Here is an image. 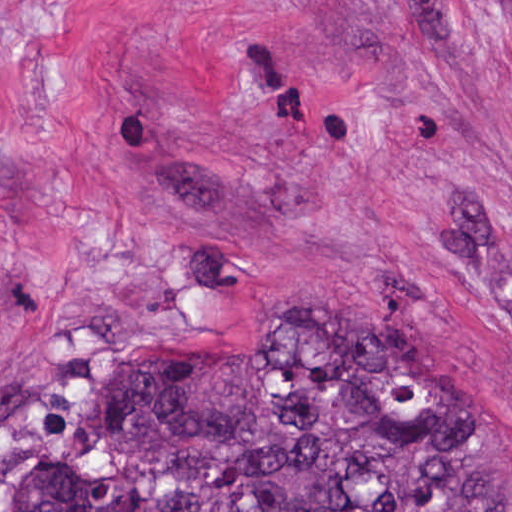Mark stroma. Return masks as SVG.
I'll use <instances>...</instances> for the list:
<instances>
[{"label": "stroma", "instance_id": "1", "mask_svg": "<svg viewBox=\"0 0 512 512\" xmlns=\"http://www.w3.org/2000/svg\"><path fill=\"white\" fill-rule=\"evenodd\" d=\"M334 313L512 452V0H0V483L73 366Z\"/></svg>", "mask_w": 512, "mask_h": 512}]
</instances>
